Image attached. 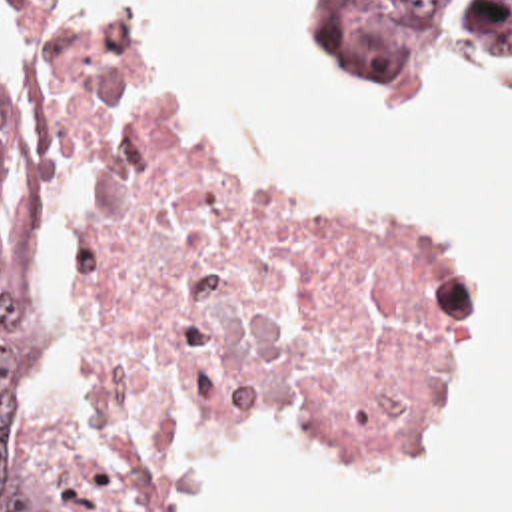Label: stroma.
Masks as SVG:
<instances>
[{
	"instance_id": "obj_1",
	"label": "stroma",
	"mask_w": 512,
	"mask_h": 512,
	"mask_svg": "<svg viewBox=\"0 0 512 512\" xmlns=\"http://www.w3.org/2000/svg\"><path fill=\"white\" fill-rule=\"evenodd\" d=\"M1 7H3V11H5V15H7V19L11 21V25L15 27V55L13 57H17V59H21L23 63H25V7H27V1L23 0H0ZM45 9V7H43ZM45 15H47V11H45ZM49 17V15H47ZM57 23V21H55ZM65 29V27H63ZM69 31V29H67ZM71 33V31H69ZM71 35H75V33H71ZM77 37V35H75ZM81 39V37H79ZM494 69H498V71H502V73H506V75H510L512 77V67H504V65H492ZM158 83V81H156ZM192 119V117H190ZM192 123H194V127H196V133H198V137H200V141H202V145L206 147V149H212V151H216V153H222V155H228V157H232V159H238V161H242L236 153H232L212 131H208V129H204L202 125H198L194 119H192ZM156 512V510H154Z\"/></svg>"
}]
</instances>
